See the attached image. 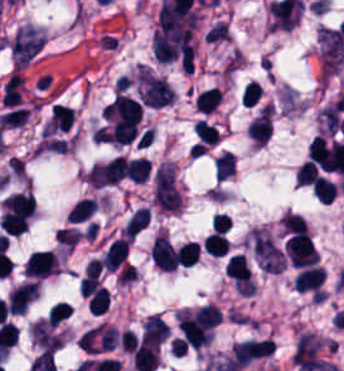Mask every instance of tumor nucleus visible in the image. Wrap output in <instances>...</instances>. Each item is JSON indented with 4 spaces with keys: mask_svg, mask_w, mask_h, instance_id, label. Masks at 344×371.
<instances>
[{
    "mask_svg": "<svg viewBox=\"0 0 344 371\" xmlns=\"http://www.w3.org/2000/svg\"><path fill=\"white\" fill-rule=\"evenodd\" d=\"M45 40L44 35L30 25L19 27L10 42L13 63L24 65L43 46Z\"/></svg>",
    "mask_w": 344,
    "mask_h": 371,
    "instance_id": "2",
    "label": "tumor nucleus"
},
{
    "mask_svg": "<svg viewBox=\"0 0 344 371\" xmlns=\"http://www.w3.org/2000/svg\"><path fill=\"white\" fill-rule=\"evenodd\" d=\"M317 41L323 69L337 72L344 63V35L341 29L320 25Z\"/></svg>",
    "mask_w": 344,
    "mask_h": 371,
    "instance_id": "1",
    "label": "tumor nucleus"
}]
</instances>
